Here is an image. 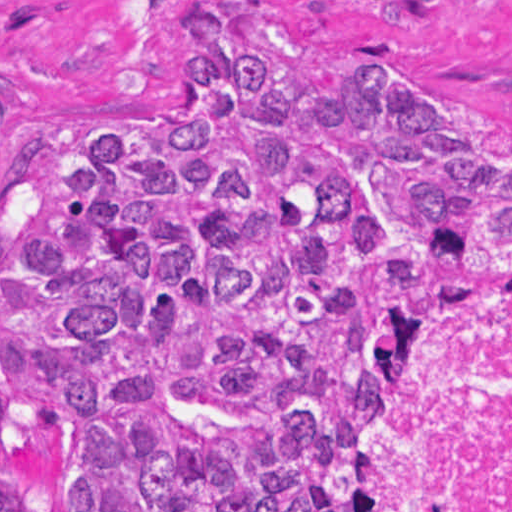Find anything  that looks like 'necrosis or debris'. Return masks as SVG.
Here are the masks:
<instances>
[{
    "label": "necrosis or debris",
    "instance_id": "1",
    "mask_svg": "<svg viewBox=\"0 0 512 512\" xmlns=\"http://www.w3.org/2000/svg\"><path fill=\"white\" fill-rule=\"evenodd\" d=\"M322 512H512V285L360 366L331 406Z\"/></svg>",
    "mask_w": 512,
    "mask_h": 512
}]
</instances>
